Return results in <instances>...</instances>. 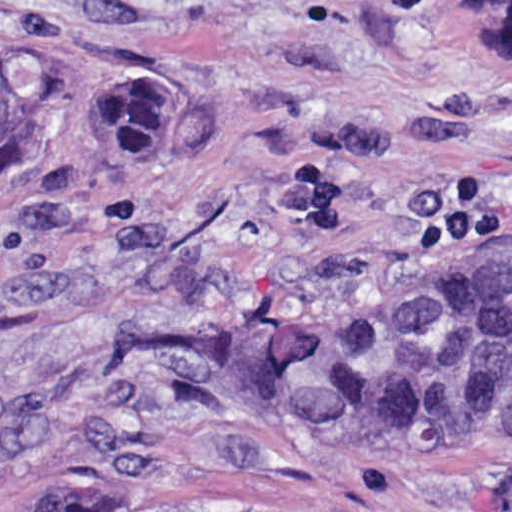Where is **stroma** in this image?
Masks as SVG:
<instances>
[{
    "label": "stroma",
    "mask_w": 512,
    "mask_h": 512,
    "mask_svg": "<svg viewBox=\"0 0 512 512\" xmlns=\"http://www.w3.org/2000/svg\"><path fill=\"white\" fill-rule=\"evenodd\" d=\"M470 0H0V61L60 71L0 167V502L109 512H512V432L338 455L260 341L461 254L512 247V47ZM187 112L149 156L101 86Z\"/></svg>",
    "instance_id": "35a3bbf8"
}]
</instances>
